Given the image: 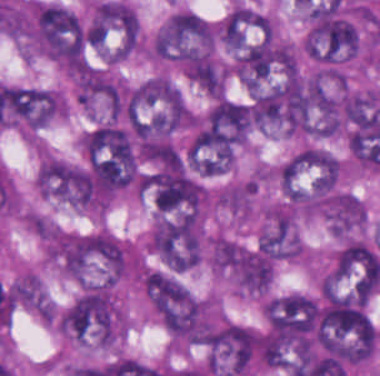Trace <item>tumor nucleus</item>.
<instances>
[{
  "label": "tumor nucleus",
  "mask_w": 380,
  "mask_h": 376,
  "mask_svg": "<svg viewBox=\"0 0 380 376\" xmlns=\"http://www.w3.org/2000/svg\"><path fill=\"white\" fill-rule=\"evenodd\" d=\"M30 33L45 54L68 66H84L99 42L91 26L58 2L32 7Z\"/></svg>",
  "instance_id": "tumor-nucleus-1"
},
{
  "label": "tumor nucleus",
  "mask_w": 380,
  "mask_h": 376,
  "mask_svg": "<svg viewBox=\"0 0 380 376\" xmlns=\"http://www.w3.org/2000/svg\"><path fill=\"white\" fill-rule=\"evenodd\" d=\"M117 318L110 284L88 283L65 313V333L109 343Z\"/></svg>",
  "instance_id": "tumor-nucleus-2"
},
{
  "label": "tumor nucleus",
  "mask_w": 380,
  "mask_h": 376,
  "mask_svg": "<svg viewBox=\"0 0 380 376\" xmlns=\"http://www.w3.org/2000/svg\"><path fill=\"white\" fill-rule=\"evenodd\" d=\"M212 28L199 15L174 11L154 39V51L163 59L185 61L208 51Z\"/></svg>",
  "instance_id": "tumor-nucleus-3"
},
{
  "label": "tumor nucleus",
  "mask_w": 380,
  "mask_h": 376,
  "mask_svg": "<svg viewBox=\"0 0 380 376\" xmlns=\"http://www.w3.org/2000/svg\"><path fill=\"white\" fill-rule=\"evenodd\" d=\"M209 369L224 376L242 373L256 354L254 333L237 323H227L208 335Z\"/></svg>",
  "instance_id": "tumor-nucleus-4"
},
{
  "label": "tumor nucleus",
  "mask_w": 380,
  "mask_h": 376,
  "mask_svg": "<svg viewBox=\"0 0 380 376\" xmlns=\"http://www.w3.org/2000/svg\"><path fill=\"white\" fill-rule=\"evenodd\" d=\"M146 290L167 327H189L195 323L197 302L181 282L169 273L151 270Z\"/></svg>",
  "instance_id": "tumor-nucleus-5"
},
{
  "label": "tumor nucleus",
  "mask_w": 380,
  "mask_h": 376,
  "mask_svg": "<svg viewBox=\"0 0 380 376\" xmlns=\"http://www.w3.org/2000/svg\"><path fill=\"white\" fill-rule=\"evenodd\" d=\"M39 188L48 195L88 206L93 203L94 183L88 170L78 164L47 158L38 173Z\"/></svg>",
  "instance_id": "tumor-nucleus-6"
},
{
  "label": "tumor nucleus",
  "mask_w": 380,
  "mask_h": 376,
  "mask_svg": "<svg viewBox=\"0 0 380 376\" xmlns=\"http://www.w3.org/2000/svg\"><path fill=\"white\" fill-rule=\"evenodd\" d=\"M60 111L61 99L56 91L20 86L0 124L35 130L59 115Z\"/></svg>",
  "instance_id": "tumor-nucleus-7"
},
{
  "label": "tumor nucleus",
  "mask_w": 380,
  "mask_h": 376,
  "mask_svg": "<svg viewBox=\"0 0 380 376\" xmlns=\"http://www.w3.org/2000/svg\"><path fill=\"white\" fill-rule=\"evenodd\" d=\"M225 262L237 283L250 292H262L271 284L272 260L256 252L237 246L228 247Z\"/></svg>",
  "instance_id": "tumor-nucleus-8"
},
{
  "label": "tumor nucleus",
  "mask_w": 380,
  "mask_h": 376,
  "mask_svg": "<svg viewBox=\"0 0 380 376\" xmlns=\"http://www.w3.org/2000/svg\"><path fill=\"white\" fill-rule=\"evenodd\" d=\"M380 273V250L359 241L343 246L336 258V275L361 281H371Z\"/></svg>",
  "instance_id": "tumor-nucleus-9"
},
{
  "label": "tumor nucleus",
  "mask_w": 380,
  "mask_h": 376,
  "mask_svg": "<svg viewBox=\"0 0 380 376\" xmlns=\"http://www.w3.org/2000/svg\"><path fill=\"white\" fill-rule=\"evenodd\" d=\"M323 207L335 231H348L362 223L363 206L356 195L333 193Z\"/></svg>",
  "instance_id": "tumor-nucleus-10"
},
{
  "label": "tumor nucleus",
  "mask_w": 380,
  "mask_h": 376,
  "mask_svg": "<svg viewBox=\"0 0 380 376\" xmlns=\"http://www.w3.org/2000/svg\"><path fill=\"white\" fill-rule=\"evenodd\" d=\"M257 249L273 259H281L293 254V232L284 219H277L260 239Z\"/></svg>",
  "instance_id": "tumor-nucleus-11"
}]
</instances>
